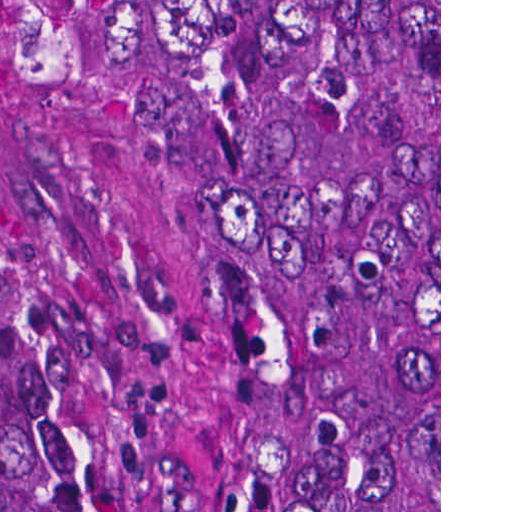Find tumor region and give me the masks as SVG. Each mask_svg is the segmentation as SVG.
I'll use <instances>...</instances> for the list:
<instances>
[{
  "mask_svg": "<svg viewBox=\"0 0 512 512\" xmlns=\"http://www.w3.org/2000/svg\"><path fill=\"white\" fill-rule=\"evenodd\" d=\"M163 3L218 512H439V0ZM0 512H136L1 320Z\"/></svg>",
  "mask_w": 512,
  "mask_h": 512,
  "instance_id": "e687c5a6",
  "label": "tumor region"
}]
</instances>
